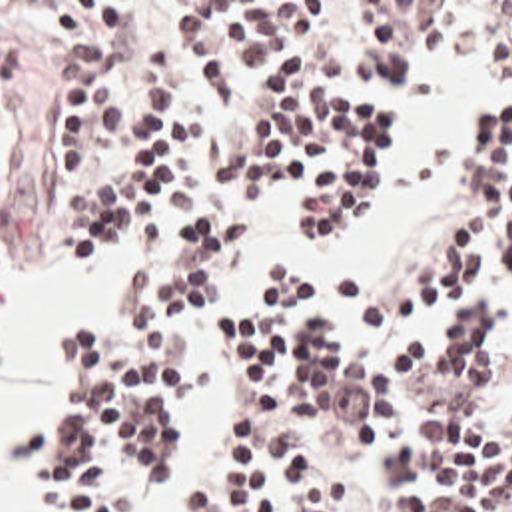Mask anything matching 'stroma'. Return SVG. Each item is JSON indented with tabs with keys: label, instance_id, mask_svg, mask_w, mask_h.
I'll list each match as a JSON object with an SVG mask.
<instances>
[{
	"label": "stroma",
	"instance_id": "35a3bbf8",
	"mask_svg": "<svg viewBox=\"0 0 512 512\" xmlns=\"http://www.w3.org/2000/svg\"><path fill=\"white\" fill-rule=\"evenodd\" d=\"M35 2H143L151 20L161 32L171 36V56L167 72L151 76L145 72L143 62H131L125 70L101 80L105 94L117 114H135L165 102L177 90L191 104L201 124L209 126H233L241 124L237 118L207 100L203 70L199 54L181 36V20L191 2H333V24L315 44L311 54V82L319 84L337 96L361 104L367 114L383 120L391 142V174L383 182L375 196L365 226L377 224L389 204L393 202L401 172L403 154L393 132V90L409 76L415 62L423 52L443 50L465 58L469 64L483 72H499L512 78L511 66L485 56L481 52L439 46L417 44L411 46L397 72L381 86L367 88L351 84L341 76L343 60L351 36L353 2H512V0H0V44L17 58V74L3 88V102L11 108L0 118V272L9 264L25 258H43L55 266L65 268L71 274H89L99 278V300L87 304L75 313L61 331L63 335L77 323L105 319L113 306V282L115 276L141 264L147 270L149 280L157 284H173L179 270V260L185 248L187 234L193 222L185 216L171 232L169 240L155 258L143 244H125L113 258L93 268H73L63 262L59 254V222L49 210L47 190L59 176L63 166V146L59 140V88L67 74L83 68V64L63 58L59 44L47 34L43 26V12ZM512 108V100L505 104L489 106L479 112L471 130L493 118L497 110ZM469 130V132H471ZM467 174L465 152L457 168V204L453 214L437 228V232L419 246L415 256L397 270H369L365 264L355 266L365 294L373 298H389L409 286H415L431 276L433 268L447 256L451 244L459 240L467 228ZM227 282V280H225ZM223 282V284H225ZM223 288V286H221ZM219 288V290H221ZM217 290V292H219ZM215 292V294H217ZM213 294V296H215ZM209 304V302H207ZM207 308V306H205ZM205 312V310H203ZM243 312V308L239 310ZM187 341L183 373L179 385V411L183 397V381L187 369V357L191 347ZM7 373V341L0 327V387ZM59 391V359L57 367L45 385L43 393L33 401L23 425L15 433V459L21 467L23 481L37 493V512L45 511L47 493L37 489L29 465L23 459V437L29 423L41 419ZM512 397V335L503 351V385L497 397L477 405L475 419L493 415L497 407ZM243 443L231 453V459L239 457ZM143 483V481H141ZM141 483L129 495L123 512L131 511Z\"/></svg>",
	"mask_w": 512,
	"mask_h": 512
}]
</instances>
